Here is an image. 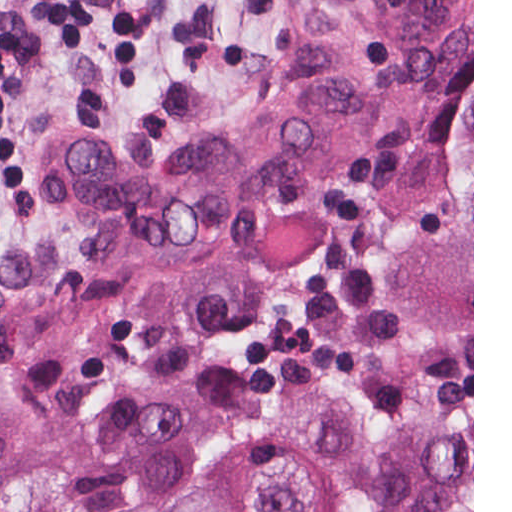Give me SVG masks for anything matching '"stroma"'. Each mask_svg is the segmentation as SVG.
<instances>
[{
	"mask_svg": "<svg viewBox=\"0 0 512 512\" xmlns=\"http://www.w3.org/2000/svg\"><path fill=\"white\" fill-rule=\"evenodd\" d=\"M306 0H0V244L81 266L76 216L48 197L52 140L134 143L240 114L295 73ZM296 378L385 428L472 422V108L392 172L371 238L270 302L190 369L0 356V512H149L224 453L260 450Z\"/></svg>",
	"mask_w": 512,
	"mask_h": 512,
	"instance_id": "stroma-1",
	"label": "stroma"
}]
</instances>
